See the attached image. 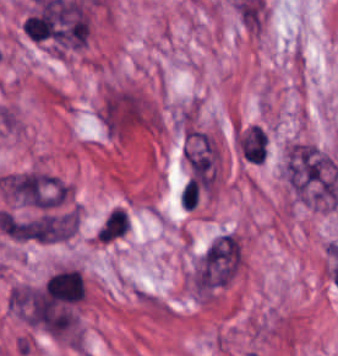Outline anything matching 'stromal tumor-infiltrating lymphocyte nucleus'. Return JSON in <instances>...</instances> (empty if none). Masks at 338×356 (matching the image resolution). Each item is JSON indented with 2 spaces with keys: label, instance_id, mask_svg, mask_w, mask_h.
Wrapping results in <instances>:
<instances>
[{
  "label": "stromal tumor-infiltrating lymphocyte nucleus",
  "instance_id": "3290ff9b",
  "mask_svg": "<svg viewBox=\"0 0 338 356\" xmlns=\"http://www.w3.org/2000/svg\"><path fill=\"white\" fill-rule=\"evenodd\" d=\"M130 221L129 216L122 221L115 229H113L106 237H104L100 242H114L119 238L125 236L129 231Z\"/></svg>",
  "mask_w": 338,
  "mask_h": 356
},
{
  "label": "stromal tumor-infiltrating lymphocyte nucleus",
  "instance_id": "52c7bb5b",
  "mask_svg": "<svg viewBox=\"0 0 338 356\" xmlns=\"http://www.w3.org/2000/svg\"><path fill=\"white\" fill-rule=\"evenodd\" d=\"M239 152L248 163L260 164L267 156L269 135L262 125L250 124L237 134Z\"/></svg>",
  "mask_w": 338,
  "mask_h": 356
},
{
  "label": "stromal tumor-infiltrating lymphocyte nucleus",
  "instance_id": "bc302bb0",
  "mask_svg": "<svg viewBox=\"0 0 338 356\" xmlns=\"http://www.w3.org/2000/svg\"><path fill=\"white\" fill-rule=\"evenodd\" d=\"M46 292L53 300L78 302L86 295L85 280L76 269H62L48 278Z\"/></svg>",
  "mask_w": 338,
  "mask_h": 356
}]
</instances>
